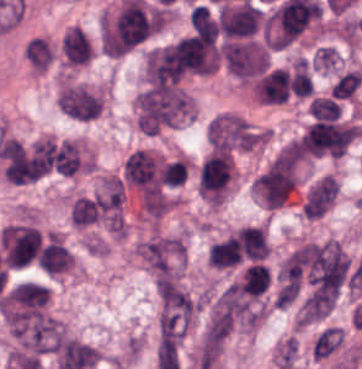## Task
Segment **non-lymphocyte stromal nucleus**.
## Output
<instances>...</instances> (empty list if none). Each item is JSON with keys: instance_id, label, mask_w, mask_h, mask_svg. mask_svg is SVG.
<instances>
[{"instance_id": "fc2b8d12", "label": "non-lymphocyte stromal nucleus", "mask_w": 362, "mask_h": 369, "mask_svg": "<svg viewBox=\"0 0 362 369\" xmlns=\"http://www.w3.org/2000/svg\"><path fill=\"white\" fill-rule=\"evenodd\" d=\"M58 109L71 118L92 121L103 111L104 98L99 90L65 82L57 95Z\"/></svg>"}, {"instance_id": "2ac0efb1", "label": "non-lymphocyte stromal nucleus", "mask_w": 362, "mask_h": 369, "mask_svg": "<svg viewBox=\"0 0 362 369\" xmlns=\"http://www.w3.org/2000/svg\"><path fill=\"white\" fill-rule=\"evenodd\" d=\"M28 59L34 69L46 70L55 57V45L50 39L34 36L26 41Z\"/></svg>"}, {"instance_id": "9d01c50a", "label": "non-lymphocyte stromal nucleus", "mask_w": 362, "mask_h": 369, "mask_svg": "<svg viewBox=\"0 0 362 369\" xmlns=\"http://www.w3.org/2000/svg\"><path fill=\"white\" fill-rule=\"evenodd\" d=\"M60 54L66 68L88 64L94 55L89 35L80 26L71 25L62 36Z\"/></svg>"}, {"instance_id": "a72fc3eb", "label": "non-lymphocyte stromal nucleus", "mask_w": 362, "mask_h": 369, "mask_svg": "<svg viewBox=\"0 0 362 369\" xmlns=\"http://www.w3.org/2000/svg\"><path fill=\"white\" fill-rule=\"evenodd\" d=\"M140 254L155 277L177 282L184 239L179 234L153 232L140 239Z\"/></svg>"}, {"instance_id": "dd21d789", "label": "non-lymphocyte stromal nucleus", "mask_w": 362, "mask_h": 369, "mask_svg": "<svg viewBox=\"0 0 362 369\" xmlns=\"http://www.w3.org/2000/svg\"><path fill=\"white\" fill-rule=\"evenodd\" d=\"M136 123L146 134L177 126L189 116V93L177 80H149L135 99Z\"/></svg>"}, {"instance_id": "3746e769", "label": "non-lymphocyte stromal nucleus", "mask_w": 362, "mask_h": 369, "mask_svg": "<svg viewBox=\"0 0 362 369\" xmlns=\"http://www.w3.org/2000/svg\"><path fill=\"white\" fill-rule=\"evenodd\" d=\"M161 334H177L192 327L200 311L199 301L180 285L158 287Z\"/></svg>"}, {"instance_id": "81446118", "label": "non-lymphocyte stromal nucleus", "mask_w": 362, "mask_h": 369, "mask_svg": "<svg viewBox=\"0 0 362 369\" xmlns=\"http://www.w3.org/2000/svg\"><path fill=\"white\" fill-rule=\"evenodd\" d=\"M209 153H233L241 149V121L238 114L222 112L206 129Z\"/></svg>"}, {"instance_id": "7c5642bf", "label": "non-lymphocyte stromal nucleus", "mask_w": 362, "mask_h": 369, "mask_svg": "<svg viewBox=\"0 0 362 369\" xmlns=\"http://www.w3.org/2000/svg\"><path fill=\"white\" fill-rule=\"evenodd\" d=\"M339 183L332 174H325L313 182L304 193L301 212L303 216L318 218L325 214L335 202Z\"/></svg>"}]
</instances>
